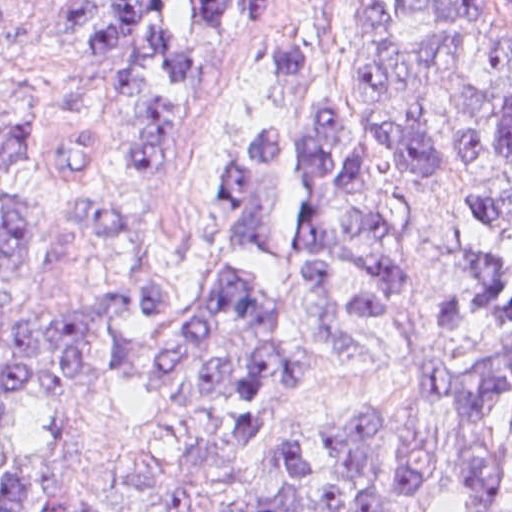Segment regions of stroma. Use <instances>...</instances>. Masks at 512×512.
Here are the masks:
<instances>
[{"mask_svg": "<svg viewBox=\"0 0 512 512\" xmlns=\"http://www.w3.org/2000/svg\"><path fill=\"white\" fill-rule=\"evenodd\" d=\"M0 105L28 117L31 156L0 183L26 192L42 230L20 308L112 304L121 297L118 264L92 245L71 205L84 194L112 192L109 181L69 170L68 141L93 136L129 171L134 189L122 201L156 228L190 267L229 233L236 215L228 171V136L240 92L272 29L322 1L512 0H0ZM58 1H116L138 21L145 39L200 68L203 121L171 167L141 180L130 160V104L112 85L96 54L62 30ZM409 173L397 184L407 238L397 255L405 281L382 299L384 315L358 325L375 339L370 358L328 366L291 380L248 455L218 477L194 512H229L262 487L265 472L290 439L304 443L317 472L308 512H322V489L338 478L326 429L354 413H379L405 449L428 445L437 464L418 494L384 512H460L449 457V428L422 401L416 385L428 366L452 374L469 370L497 328L454 341L444 332L445 299L458 276L462 205L447 180L421 188ZM90 436L67 458V486L111 509H138L130 465L134 455L164 440V416L145 396L116 383L87 387L79 398ZM54 435V412L41 401L19 400L0 412V461L40 450ZM479 512H512V459L477 502Z\"/></svg>", "mask_w": 512, "mask_h": 512, "instance_id": "obj_1", "label": "stroma"}]
</instances>
